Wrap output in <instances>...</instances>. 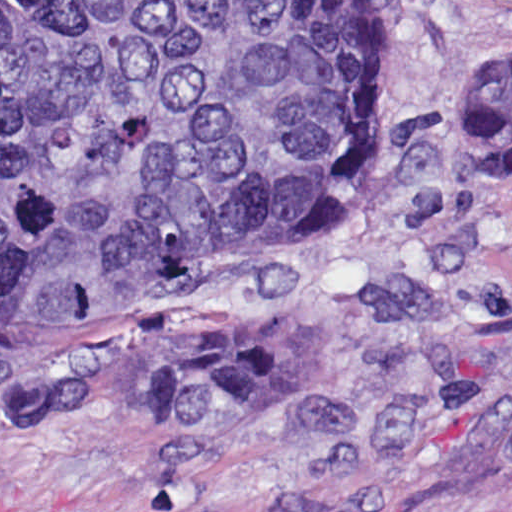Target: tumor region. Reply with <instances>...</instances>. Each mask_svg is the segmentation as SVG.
<instances>
[{"label": "tumor region", "instance_id": "1", "mask_svg": "<svg viewBox=\"0 0 512 512\" xmlns=\"http://www.w3.org/2000/svg\"><path fill=\"white\" fill-rule=\"evenodd\" d=\"M393 58L374 0H0V327L109 329L15 408L218 428L287 401L307 320L176 304L366 169ZM456 125L512 167V61L462 75Z\"/></svg>", "mask_w": 512, "mask_h": 512}]
</instances>
